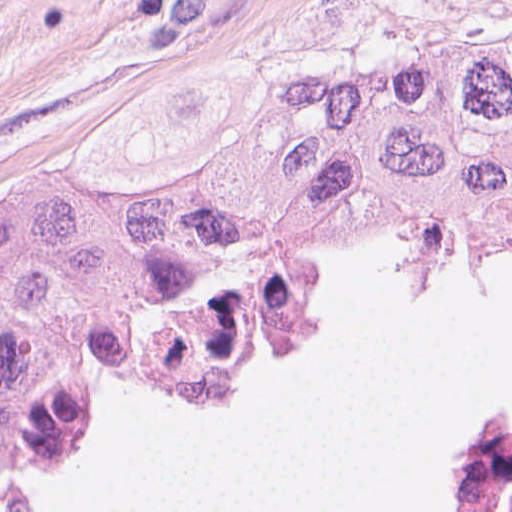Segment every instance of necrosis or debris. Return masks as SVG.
Returning a JSON list of instances; mask_svg holds the SVG:
<instances>
[{
  "label": "necrosis or debris",
  "instance_id": "4bbe7bcc",
  "mask_svg": "<svg viewBox=\"0 0 512 512\" xmlns=\"http://www.w3.org/2000/svg\"><path fill=\"white\" fill-rule=\"evenodd\" d=\"M455 512H512V430L490 421L467 425L459 446Z\"/></svg>",
  "mask_w": 512,
  "mask_h": 512
}]
</instances>
